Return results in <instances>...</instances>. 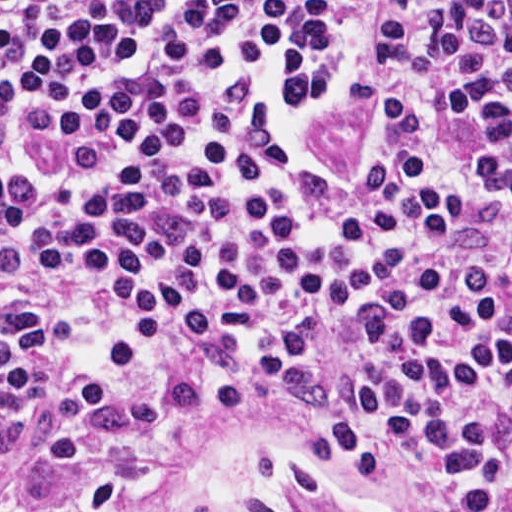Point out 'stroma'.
<instances>
[{
	"mask_svg": "<svg viewBox=\"0 0 512 512\" xmlns=\"http://www.w3.org/2000/svg\"><path fill=\"white\" fill-rule=\"evenodd\" d=\"M363 502L360 467L286 412L198 403L123 497L85 511L42 501L30 456L0 432V512H363Z\"/></svg>",
	"mask_w": 512,
	"mask_h": 512,
	"instance_id": "obj_1",
	"label": "stroma"
}]
</instances>
